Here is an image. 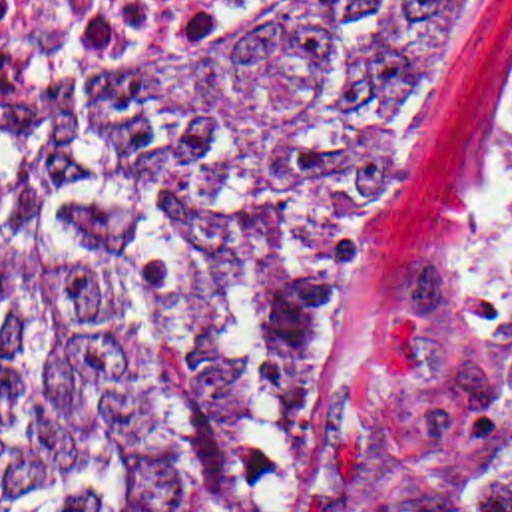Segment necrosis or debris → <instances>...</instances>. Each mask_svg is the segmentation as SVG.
I'll use <instances>...</instances> for the list:
<instances>
[{
    "label": "necrosis or debris",
    "instance_id": "necrosis-or-debris-1",
    "mask_svg": "<svg viewBox=\"0 0 512 512\" xmlns=\"http://www.w3.org/2000/svg\"><path fill=\"white\" fill-rule=\"evenodd\" d=\"M317 1L0 0V95L133 81Z\"/></svg>",
    "mask_w": 512,
    "mask_h": 512
}]
</instances>
